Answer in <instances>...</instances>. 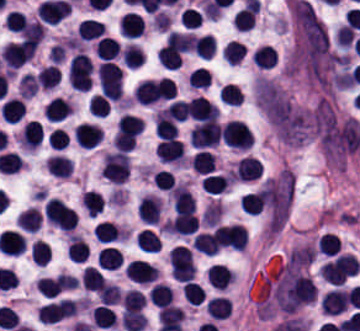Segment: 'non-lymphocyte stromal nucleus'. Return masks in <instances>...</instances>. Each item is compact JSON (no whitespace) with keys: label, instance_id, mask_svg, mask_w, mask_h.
<instances>
[{"label":"non-lymphocyte stromal nucleus","instance_id":"obj_1","mask_svg":"<svg viewBox=\"0 0 360 331\" xmlns=\"http://www.w3.org/2000/svg\"><path fill=\"white\" fill-rule=\"evenodd\" d=\"M269 297L280 312L291 315L314 300V288L304 270L281 263L270 278Z\"/></svg>","mask_w":360,"mask_h":331}]
</instances>
